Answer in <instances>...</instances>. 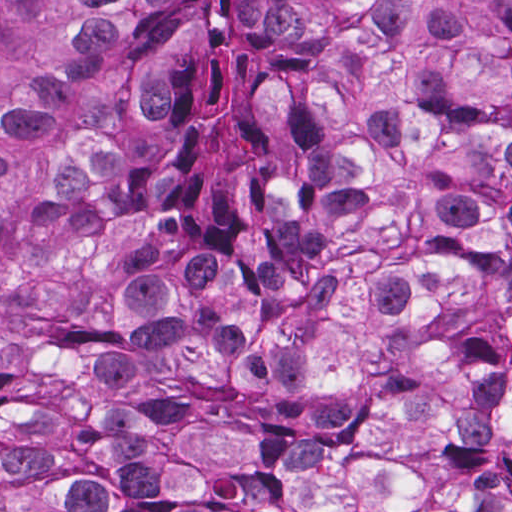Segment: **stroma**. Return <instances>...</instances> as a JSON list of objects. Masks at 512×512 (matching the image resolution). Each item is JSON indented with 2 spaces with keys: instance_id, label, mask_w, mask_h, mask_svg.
I'll use <instances>...</instances> for the list:
<instances>
[{
  "instance_id": "35a3bbf8",
  "label": "stroma",
  "mask_w": 512,
  "mask_h": 512,
  "mask_svg": "<svg viewBox=\"0 0 512 512\" xmlns=\"http://www.w3.org/2000/svg\"><path fill=\"white\" fill-rule=\"evenodd\" d=\"M1 1H512V0H0V512H1Z\"/></svg>"
}]
</instances>
